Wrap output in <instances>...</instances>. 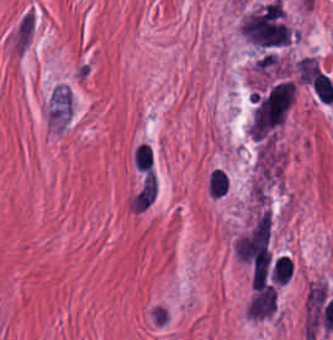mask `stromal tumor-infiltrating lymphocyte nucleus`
<instances>
[{
    "label": "stromal tumor-infiltrating lymphocyte nucleus",
    "instance_id": "obj_1",
    "mask_svg": "<svg viewBox=\"0 0 333 340\" xmlns=\"http://www.w3.org/2000/svg\"><path fill=\"white\" fill-rule=\"evenodd\" d=\"M205 194L213 200L225 199L231 190V178L223 167L210 170L204 182Z\"/></svg>",
    "mask_w": 333,
    "mask_h": 340
},
{
    "label": "stromal tumor-infiltrating lymphocyte nucleus",
    "instance_id": "obj_2",
    "mask_svg": "<svg viewBox=\"0 0 333 340\" xmlns=\"http://www.w3.org/2000/svg\"><path fill=\"white\" fill-rule=\"evenodd\" d=\"M155 158L154 147L146 140H138L131 149L130 166L136 173L149 166Z\"/></svg>",
    "mask_w": 333,
    "mask_h": 340
},
{
    "label": "stromal tumor-infiltrating lymphocyte nucleus",
    "instance_id": "obj_4",
    "mask_svg": "<svg viewBox=\"0 0 333 340\" xmlns=\"http://www.w3.org/2000/svg\"><path fill=\"white\" fill-rule=\"evenodd\" d=\"M293 260L288 256H280L274 266V284H285L292 276Z\"/></svg>",
    "mask_w": 333,
    "mask_h": 340
},
{
    "label": "stromal tumor-infiltrating lymphocyte nucleus",
    "instance_id": "obj_3",
    "mask_svg": "<svg viewBox=\"0 0 333 340\" xmlns=\"http://www.w3.org/2000/svg\"><path fill=\"white\" fill-rule=\"evenodd\" d=\"M310 85L321 103H331L333 99V83L329 75L316 68Z\"/></svg>",
    "mask_w": 333,
    "mask_h": 340
}]
</instances>
